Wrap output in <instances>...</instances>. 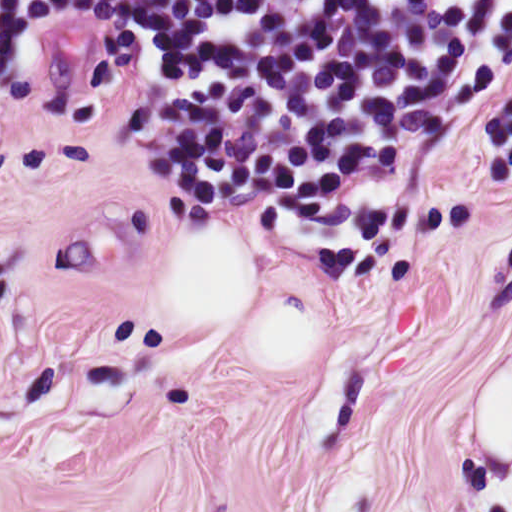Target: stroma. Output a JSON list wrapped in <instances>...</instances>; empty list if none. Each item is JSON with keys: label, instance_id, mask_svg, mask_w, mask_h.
<instances>
[{"label": "stroma", "instance_id": "obj_1", "mask_svg": "<svg viewBox=\"0 0 512 512\" xmlns=\"http://www.w3.org/2000/svg\"><path fill=\"white\" fill-rule=\"evenodd\" d=\"M512 80V23L477 96ZM201 218L144 148V50L121 21L76 25L0 74V308Z\"/></svg>", "mask_w": 512, "mask_h": 512}]
</instances>
